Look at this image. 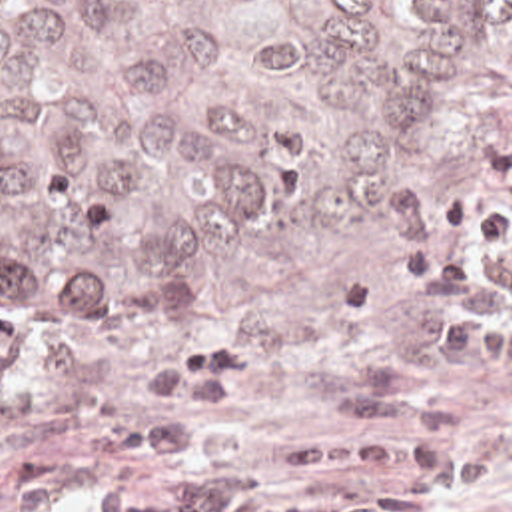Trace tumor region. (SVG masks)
Here are the masks:
<instances>
[{
  "label": "tumor region",
  "mask_w": 512,
  "mask_h": 512,
  "mask_svg": "<svg viewBox=\"0 0 512 512\" xmlns=\"http://www.w3.org/2000/svg\"><path fill=\"white\" fill-rule=\"evenodd\" d=\"M512 0H0V309L249 319L375 271Z\"/></svg>",
  "instance_id": "1"
}]
</instances>
